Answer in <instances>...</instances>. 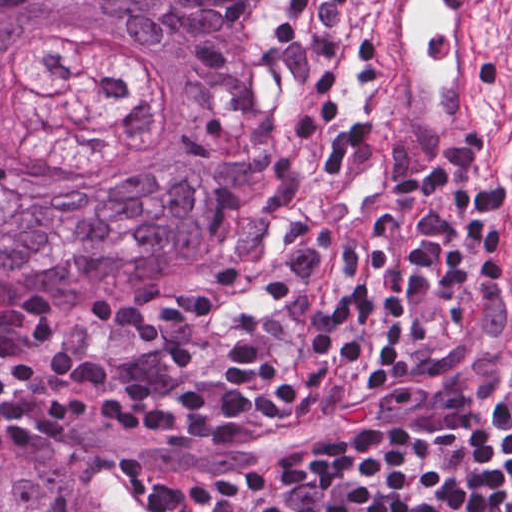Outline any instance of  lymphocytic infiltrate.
Masks as SVG:
<instances>
[{
    "instance_id": "obj_1",
    "label": "lymphocytic infiltrate",
    "mask_w": 512,
    "mask_h": 512,
    "mask_svg": "<svg viewBox=\"0 0 512 512\" xmlns=\"http://www.w3.org/2000/svg\"><path fill=\"white\" fill-rule=\"evenodd\" d=\"M350 2L276 0L268 63L309 180L293 238L239 290L11 326L0 450L65 455L89 412L168 443H312L243 470L133 459L154 512H512V287L504 319L487 152L477 134L427 173L359 128L337 65Z\"/></svg>"
}]
</instances>
